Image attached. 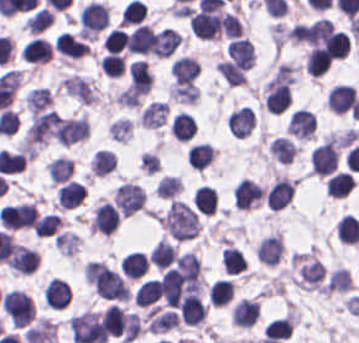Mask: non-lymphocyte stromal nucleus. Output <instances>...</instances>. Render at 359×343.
Here are the masks:
<instances>
[{"label": "non-lymphocyte stromal nucleus", "instance_id": "obj_1", "mask_svg": "<svg viewBox=\"0 0 359 343\" xmlns=\"http://www.w3.org/2000/svg\"><path fill=\"white\" fill-rule=\"evenodd\" d=\"M69 329L76 343H103L107 338L99 316L92 310L73 314Z\"/></svg>", "mask_w": 359, "mask_h": 343}, {"label": "non-lymphocyte stromal nucleus", "instance_id": "obj_2", "mask_svg": "<svg viewBox=\"0 0 359 343\" xmlns=\"http://www.w3.org/2000/svg\"><path fill=\"white\" fill-rule=\"evenodd\" d=\"M113 198L119 213L128 217L140 209L145 196L139 185L124 181L114 188Z\"/></svg>", "mask_w": 359, "mask_h": 343}, {"label": "non-lymphocyte stromal nucleus", "instance_id": "obj_3", "mask_svg": "<svg viewBox=\"0 0 359 343\" xmlns=\"http://www.w3.org/2000/svg\"><path fill=\"white\" fill-rule=\"evenodd\" d=\"M181 41V33L165 26L153 32L148 50L157 57H167Z\"/></svg>", "mask_w": 359, "mask_h": 343}, {"label": "non-lymphocyte stromal nucleus", "instance_id": "obj_4", "mask_svg": "<svg viewBox=\"0 0 359 343\" xmlns=\"http://www.w3.org/2000/svg\"><path fill=\"white\" fill-rule=\"evenodd\" d=\"M61 85L69 95L81 103H94L98 98L87 77L71 74L61 79Z\"/></svg>", "mask_w": 359, "mask_h": 343}, {"label": "non-lymphocyte stromal nucleus", "instance_id": "obj_5", "mask_svg": "<svg viewBox=\"0 0 359 343\" xmlns=\"http://www.w3.org/2000/svg\"><path fill=\"white\" fill-rule=\"evenodd\" d=\"M283 249L280 235L271 234L258 242L256 248L257 259L267 265H275L279 260Z\"/></svg>", "mask_w": 359, "mask_h": 343}, {"label": "non-lymphocyte stromal nucleus", "instance_id": "obj_6", "mask_svg": "<svg viewBox=\"0 0 359 343\" xmlns=\"http://www.w3.org/2000/svg\"><path fill=\"white\" fill-rule=\"evenodd\" d=\"M62 129L68 145L89 134V123L83 116H64Z\"/></svg>", "mask_w": 359, "mask_h": 343}, {"label": "non-lymphocyte stromal nucleus", "instance_id": "obj_7", "mask_svg": "<svg viewBox=\"0 0 359 343\" xmlns=\"http://www.w3.org/2000/svg\"><path fill=\"white\" fill-rule=\"evenodd\" d=\"M167 104L161 100H152L140 111L139 119L143 126L156 127L163 122L166 116Z\"/></svg>", "mask_w": 359, "mask_h": 343}, {"label": "non-lymphocyte stromal nucleus", "instance_id": "obj_8", "mask_svg": "<svg viewBox=\"0 0 359 343\" xmlns=\"http://www.w3.org/2000/svg\"><path fill=\"white\" fill-rule=\"evenodd\" d=\"M24 99L31 112L46 107L52 101V96L48 87L38 85L30 90Z\"/></svg>", "mask_w": 359, "mask_h": 343}, {"label": "non-lymphocyte stromal nucleus", "instance_id": "obj_9", "mask_svg": "<svg viewBox=\"0 0 359 343\" xmlns=\"http://www.w3.org/2000/svg\"><path fill=\"white\" fill-rule=\"evenodd\" d=\"M352 285L351 271L344 266H336L325 285L329 290H349Z\"/></svg>", "mask_w": 359, "mask_h": 343}]
</instances>
